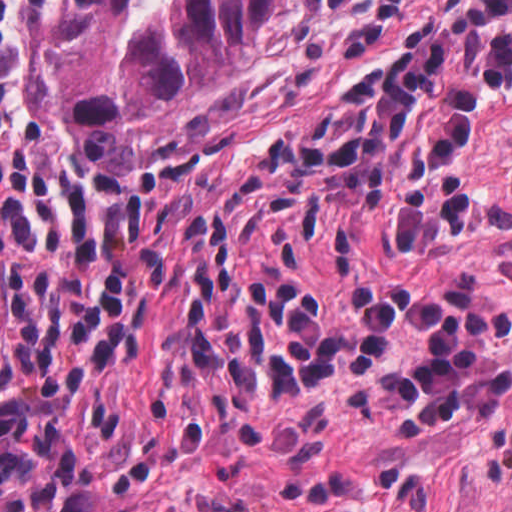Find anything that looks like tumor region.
I'll return each instance as SVG.
<instances>
[{
  "instance_id": "tumor-region-1",
  "label": "tumor region",
  "mask_w": 512,
  "mask_h": 512,
  "mask_svg": "<svg viewBox=\"0 0 512 512\" xmlns=\"http://www.w3.org/2000/svg\"><path fill=\"white\" fill-rule=\"evenodd\" d=\"M279 0H79L42 51V114L108 173L199 121L263 42Z\"/></svg>"
}]
</instances>
